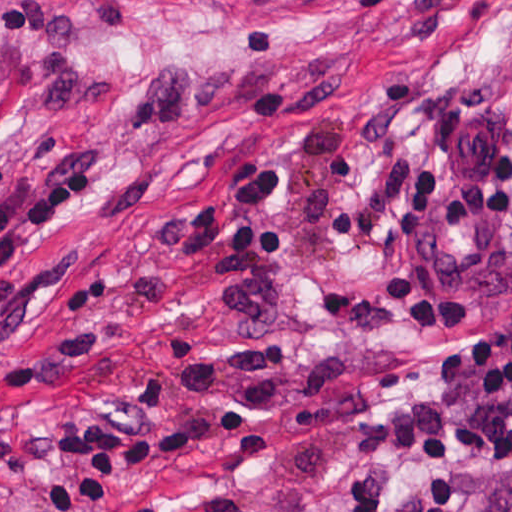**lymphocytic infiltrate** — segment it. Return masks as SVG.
<instances>
[{
  "label": "lymphocytic infiltrate",
  "mask_w": 512,
  "mask_h": 512,
  "mask_svg": "<svg viewBox=\"0 0 512 512\" xmlns=\"http://www.w3.org/2000/svg\"><path fill=\"white\" fill-rule=\"evenodd\" d=\"M512 121V53L464 98L431 109L427 144L411 166L398 208L405 232L386 277L389 305L407 329H461L474 296L438 276L425 258V233L477 235L512 211V153L499 154L491 192L447 189L455 149L490 122ZM287 176L277 153H239L212 177L199 201L156 230L184 263L203 267L229 257V311L244 327H269L285 313L275 267L294 259V232L278 219ZM95 170L16 178L0 188V411L27 381L110 333L94 315L120 289L116 271L75 269L84 252L15 259L65 213L97 197ZM432 384L405 402L409 464L388 492L335 512H453L461 459L512 468V313L482 322L470 338L437 353Z\"/></svg>",
  "instance_id": "1"
}]
</instances>
